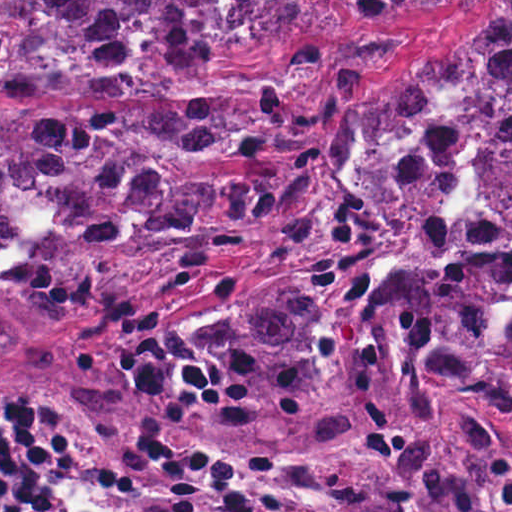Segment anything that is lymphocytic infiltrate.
<instances>
[{"label":"lymphocytic infiltrate","instance_id":"lymphocytic-infiltrate-1","mask_svg":"<svg viewBox=\"0 0 512 512\" xmlns=\"http://www.w3.org/2000/svg\"><path fill=\"white\" fill-rule=\"evenodd\" d=\"M56 397L0 379V512H27L56 484V455L19 426ZM79 468L78 489L46 512H186L177 471L133 434L94 421L47 419ZM306 512H316L303 498Z\"/></svg>","mask_w":512,"mask_h":512}]
</instances>
